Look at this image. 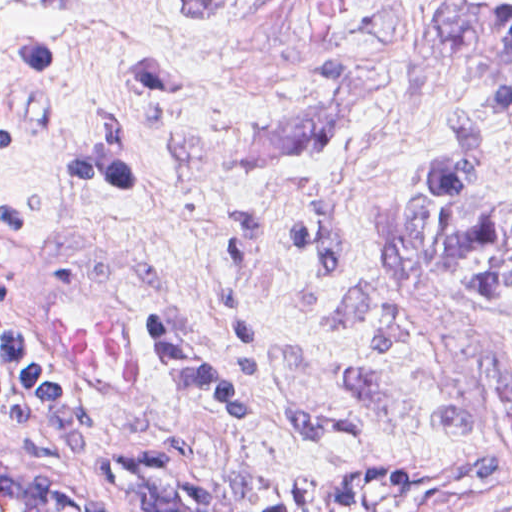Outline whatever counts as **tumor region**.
Instances as JSON below:
<instances>
[{"label": "tumor region", "instance_id": "1", "mask_svg": "<svg viewBox=\"0 0 512 512\" xmlns=\"http://www.w3.org/2000/svg\"><path fill=\"white\" fill-rule=\"evenodd\" d=\"M428 0L411 41V98L435 151L406 203L411 259L512 300V220L474 208L481 146L512 98V0Z\"/></svg>", "mask_w": 512, "mask_h": 512}]
</instances>
